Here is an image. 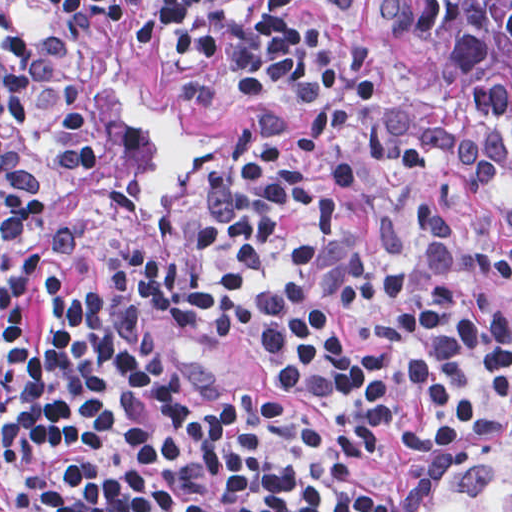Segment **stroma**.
I'll use <instances>...</instances> for the list:
<instances>
[{"instance_id":"stroma-1","label":"stroma","mask_w":512,"mask_h":512,"mask_svg":"<svg viewBox=\"0 0 512 512\" xmlns=\"http://www.w3.org/2000/svg\"><path fill=\"white\" fill-rule=\"evenodd\" d=\"M155 0H125L115 47L59 20L20 34L17 83L2 111V164L21 194L1 224L0 0V512L1 247L48 286L101 294L152 342L195 396L251 390L283 416L333 430L341 405L278 379L235 347L187 340L171 321L174 290L168 242L173 225L209 194L220 155L257 110L305 124L285 100L247 93L231 80L219 52L185 54L175 38L142 44L136 29ZM359 8V0H355ZM374 78L428 111L452 137H438L433 168L415 179L396 174L345 190L342 217L362 243L385 257L408 246L413 200L430 199L457 230L512 249L502 214L511 195L512 161L486 155L470 109L427 81L392 67L367 44ZM464 152L495 176L491 191L463 185ZM512 439V357L500 392V419L489 434L425 470L413 512H445L441 485L469 460Z\"/></svg>"}]
</instances>
